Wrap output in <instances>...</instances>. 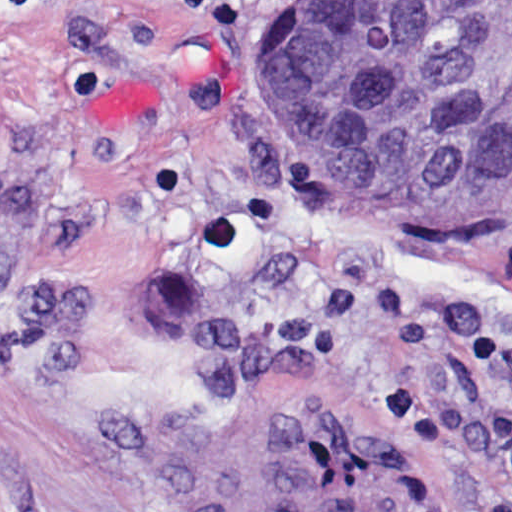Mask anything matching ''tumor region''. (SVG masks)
<instances>
[{
  "instance_id": "e687c5a6",
  "label": "tumor region",
  "mask_w": 512,
  "mask_h": 512,
  "mask_svg": "<svg viewBox=\"0 0 512 512\" xmlns=\"http://www.w3.org/2000/svg\"><path fill=\"white\" fill-rule=\"evenodd\" d=\"M260 83L332 187L440 218L512 205V0H286Z\"/></svg>"
}]
</instances>
